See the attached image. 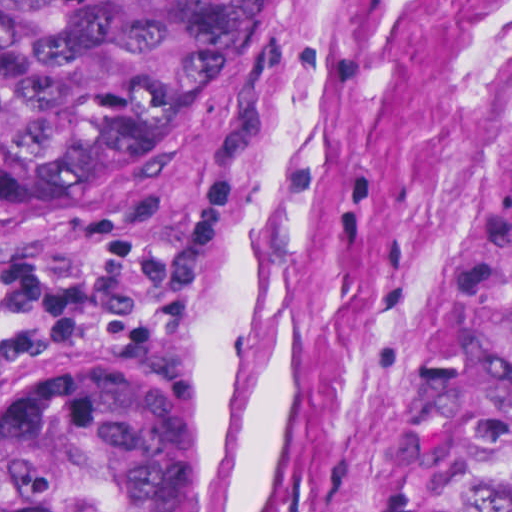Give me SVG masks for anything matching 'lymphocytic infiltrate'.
<instances>
[{
    "label": "lymphocytic infiltrate",
    "mask_w": 512,
    "mask_h": 512,
    "mask_svg": "<svg viewBox=\"0 0 512 512\" xmlns=\"http://www.w3.org/2000/svg\"><path fill=\"white\" fill-rule=\"evenodd\" d=\"M196 170L159 186L82 252L0 262V381L77 347H149L193 325L213 292L217 227L236 192Z\"/></svg>",
    "instance_id": "1"
}]
</instances>
